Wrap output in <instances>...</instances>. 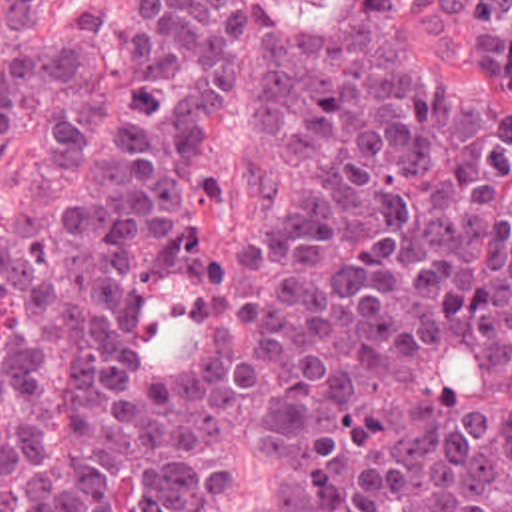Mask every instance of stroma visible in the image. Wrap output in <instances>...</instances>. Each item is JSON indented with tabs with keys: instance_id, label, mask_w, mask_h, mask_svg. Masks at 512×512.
<instances>
[{
	"instance_id": "obj_1",
	"label": "stroma",
	"mask_w": 512,
	"mask_h": 512,
	"mask_svg": "<svg viewBox=\"0 0 512 512\" xmlns=\"http://www.w3.org/2000/svg\"><path fill=\"white\" fill-rule=\"evenodd\" d=\"M134 0H54L35 19L52 41L64 45L86 7L98 9L112 27ZM264 0H238V15L224 75V101L206 165L212 187L188 199L190 231L202 257H216L232 237L244 205V163L256 103L260 17ZM394 37L408 63L430 81L480 89L496 107L512 111V87L490 77L474 55V41L442 0L416 3L398 13ZM266 476L264 456L230 422L216 424V478L210 512H258Z\"/></svg>"
}]
</instances>
